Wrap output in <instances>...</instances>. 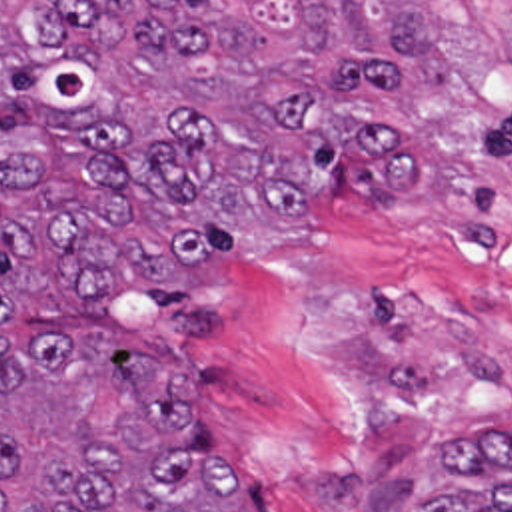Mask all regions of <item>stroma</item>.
<instances>
[{
    "instance_id": "obj_1",
    "label": "stroma",
    "mask_w": 512,
    "mask_h": 512,
    "mask_svg": "<svg viewBox=\"0 0 512 512\" xmlns=\"http://www.w3.org/2000/svg\"><path fill=\"white\" fill-rule=\"evenodd\" d=\"M440 14L454 88L376 114L422 134L434 182L366 200L338 172L328 234L240 252L176 350L208 451L276 512H412L440 447L512 438V0Z\"/></svg>"
}]
</instances>
